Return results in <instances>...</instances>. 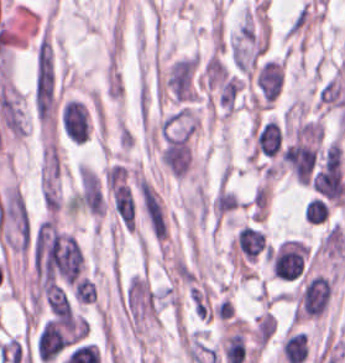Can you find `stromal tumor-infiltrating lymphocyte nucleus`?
<instances>
[{"mask_svg":"<svg viewBox=\"0 0 345 363\" xmlns=\"http://www.w3.org/2000/svg\"><path fill=\"white\" fill-rule=\"evenodd\" d=\"M60 122L62 130L71 140L83 142L88 136V112L79 99L72 98L62 106Z\"/></svg>","mask_w":345,"mask_h":363,"instance_id":"1","label":"stromal tumor-infiltrating lymphocyte nucleus"},{"mask_svg":"<svg viewBox=\"0 0 345 363\" xmlns=\"http://www.w3.org/2000/svg\"><path fill=\"white\" fill-rule=\"evenodd\" d=\"M255 79L262 101L269 107L283 86L284 66L278 60L270 58L261 64Z\"/></svg>","mask_w":345,"mask_h":363,"instance_id":"2","label":"stromal tumor-infiltrating lymphocyte nucleus"},{"mask_svg":"<svg viewBox=\"0 0 345 363\" xmlns=\"http://www.w3.org/2000/svg\"><path fill=\"white\" fill-rule=\"evenodd\" d=\"M282 137L278 123L270 118L253 128V151L274 156L279 152Z\"/></svg>","mask_w":345,"mask_h":363,"instance_id":"3","label":"stromal tumor-infiltrating lymphocyte nucleus"},{"mask_svg":"<svg viewBox=\"0 0 345 363\" xmlns=\"http://www.w3.org/2000/svg\"><path fill=\"white\" fill-rule=\"evenodd\" d=\"M311 223H321L327 219L330 213V206L320 197H313L304 211Z\"/></svg>","mask_w":345,"mask_h":363,"instance_id":"4","label":"stromal tumor-infiltrating lymphocyte nucleus"}]
</instances>
